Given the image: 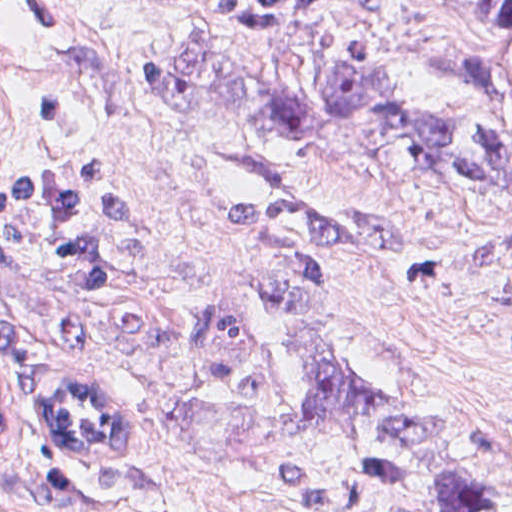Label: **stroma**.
Listing matches in <instances>:
<instances>
[{
	"label": "stroma",
	"mask_w": 512,
	"mask_h": 512,
	"mask_svg": "<svg viewBox=\"0 0 512 512\" xmlns=\"http://www.w3.org/2000/svg\"><path fill=\"white\" fill-rule=\"evenodd\" d=\"M342 1L259 36L222 26L254 9ZM489 0H0V176L113 173L127 214L118 279L72 291L31 252L0 255V311L24 346L34 411L59 372L118 378L143 410L138 457L88 471L35 414L0 449V512H398L354 455L310 423L277 372L276 298L261 217L350 202L384 225L329 301L390 393L447 410L512 413V320L451 293L436 272L500 225L480 168L462 66L494 45ZM200 36V37H199ZM198 43L290 89L374 66L418 125L417 150L456 186L328 138L239 133L178 83ZM21 374L19 377V381ZM395 440L470 468L512 512V448L477 428L394 415Z\"/></svg>",
	"instance_id": "stroma-1"
}]
</instances>
